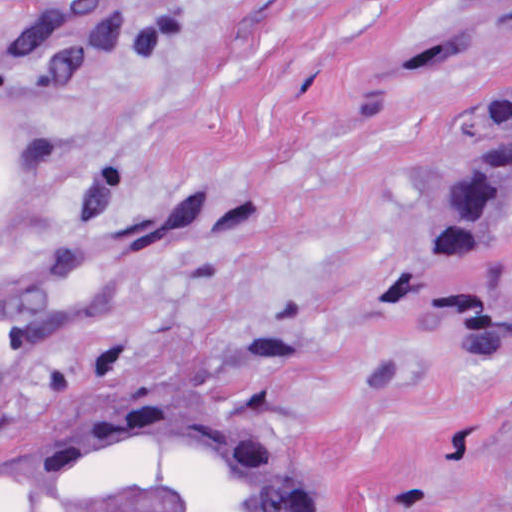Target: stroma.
<instances>
[{"label":"stroma","instance_id":"35a3bbf8","mask_svg":"<svg viewBox=\"0 0 512 512\" xmlns=\"http://www.w3.org/2000/svg\"><path fill=\"white\" fill-rule=\"evenodd\" d=\"M481 0H0V512L118 409L213 412L315 512H512V211L396 277L512 98Z\"/></svg>","mask_w":512,"mask_h":512}]
</instances>
